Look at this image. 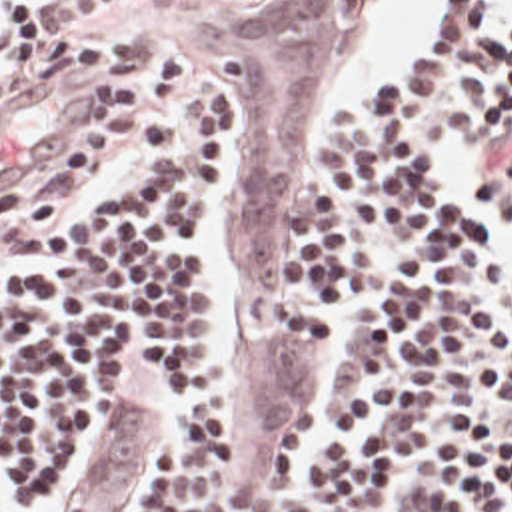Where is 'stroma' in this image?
Listing matches in <instances>:
<instances>
[{"mask_svg": "<svg viewBox=\"0 0 512 512\" xmlns=\"http://www.w3.org/2000/svg\"><path fill=\"white\" fill-rule=\"evenodd\" d=\"M398 1L54 0V35L0 73V263L124 189L130 141L178 77L218 89L232 133L210 225L226 512H314L312 458L374 440L370 417L336 423V399L348 353L382 307L362 299L334 313V329L304 311L302 189L330 177L344 111L384 91L356 87ZM164 448L162 401L140 385L118 393L56 512H150Z\"/></svg>", "mask_w": 512, "mask_h": 512, "instance_id": "obj_1", "label": "stroma"}]
</instances>
